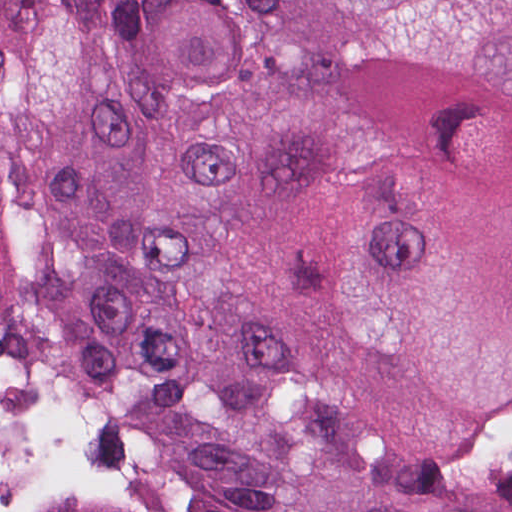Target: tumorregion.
<instances>
[{
    "instance_id": "e687c5a6",
    "label": "tumor region",
    "mask_w": 512,
    "mask_h": 512,
    "mask_svg": "<svg viewBox=\"0 0 512 512\" xmlns=\"http://www.w3.org/2000/svg\"><path fill=\"white\" fill-rule=\"evenodd\" d=\"M0 337L184 512H512V0H0Z\"/></svg>"
}]
</instances>
